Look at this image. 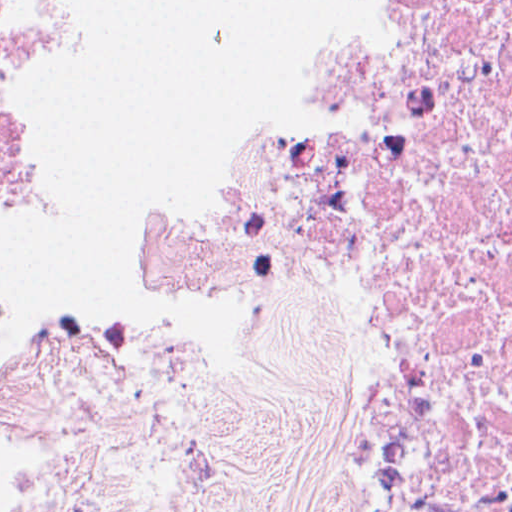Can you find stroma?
Returning a JSON list of instances; mask_svg holds the SVG:
<instances>
[{
	"instance_id": "1",
	"label": "stroma",
	"mask_w": 512,
	"mask_h": 512,
	"mask_svg": "<svg viewBox=\"0 0 512 512\" xmlns=\"http://www.w3.org/2000/svg\"><path fill=\"white\" fill-rule=\"evenodd\" d=\"M74 469L124 512H349V432L325 364L186 322L74 348L50 371L15 487Z\"/></svg>"
}]
</instances>
